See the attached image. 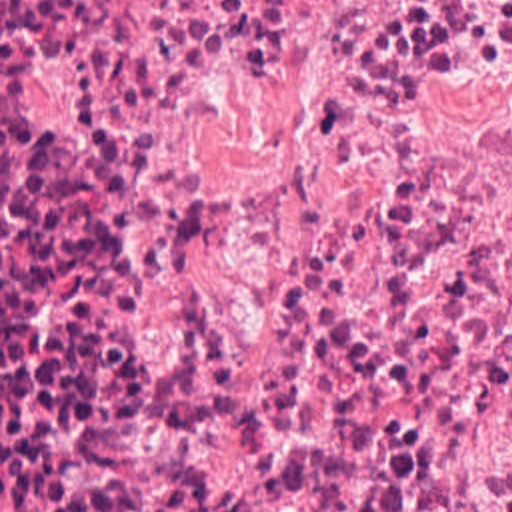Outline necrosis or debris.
Here are the masks:
<instances>
[{
  "instance_id": "1",
  "label": "necrosis or debris",
  "mask_w": 512,
  "mask_h": 512,
  "mask_svg": "<svg viewBox=\"0 0 512 512\" xmlns=\"http://www.w3.org/2000/svg\"><path fill=\"white\" fill-rule=\"evenodd\" d=\"M0 512H512V0H0Z\"/></svg>"
}]
</instances>
